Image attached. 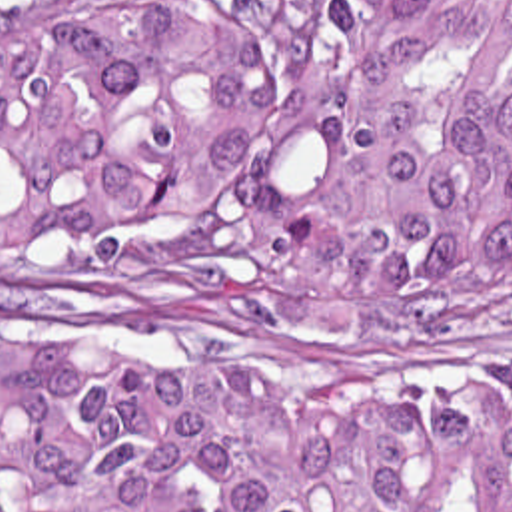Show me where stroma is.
<instances>
[{
  "mask_svg": "<svg viewBox=\"0 0 512 512\" xmlns=\"http://www.w3.org/2000/svg\"><path fill=\"white\" fill-rule=\"evenodd\" d=\"M465 339L361 343L249 311L145 307L97 265L0 253V345L241 390H395L431 432L445 400L512 394V289L457 319Z\"/></svg>",
  "mask_w": 512,
  "mask_h": 512,
  "instance_id": "35a3bbf8",
  "label": "stroma"
}]
</instances>
